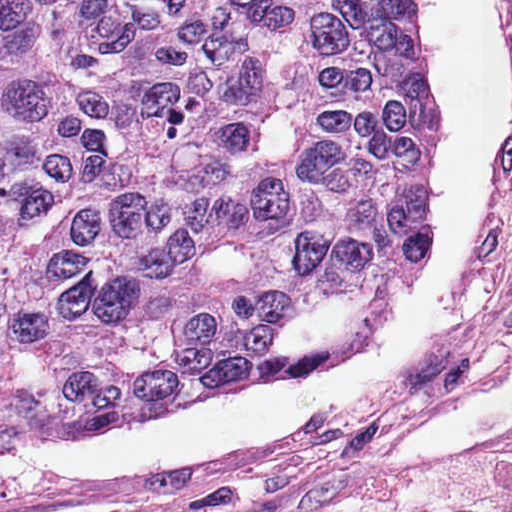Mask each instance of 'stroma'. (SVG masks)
I'll return each instance as SVG.
<instances>
[{
	"label": "stroma",
	"mask_w": 512,
	"mask_h": 512,
	"mask_svg": "<svg viewBox=\"0 0 512 512\" xmlns=\"http://www.w3.org/2000/svg\"><path fill=\"white\" fill-rule=\"evenodd\" d=\"M512 34V0H502ZM512 361V213L458 338L419 374L269 455L187 495L74 512H355L415 480L358 470L364 450ZM468 512H512V502Z\"/></svg>",
	"instance_id": "1"
}]
</instances>
